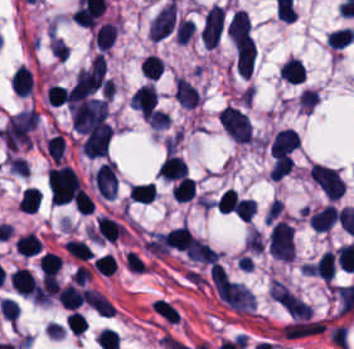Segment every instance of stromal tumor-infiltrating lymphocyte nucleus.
Wrapping results in <instances>:
<instances>
[{
    "label": "stromal tumor-infiltrating lymphocyte nucleus",
    "instance_id": "bc302bb0",
    "mask_svg": "<svg viewBox=\"0 0 354 349\" xmlns=\"http://www.w3.org/2000/svg\"><path fill=\"white\" fill-rule=\"evenodd\" d=\"M224 21L225 11L221 6L214 4L210 9L201 30L202 42L206 48L217 46L221 37Z\"/></svg>",
    "mask_w": 354,
    "mask_h": 349
},
{
    "label": "stromal tumor-infiltrating lymphocyte nucleus",
    "instance_id": "52c7bb5b",
    "mask_svg": "<svg viewBox=\"0 0 354 349\" xmlns=\"http://www.w3.org/2000/svg\"><path fill=\"white\" fill-rule=\"evenodd\" d=\"M158 94L154 86L143 84L132 94L129 104L145 116H153Z\"/></svg>",
    "mask_w": 354,
    "mask_h": 349
},
{
    "label": "stromal tumor-infiltrating lymphocyte nucleus",
    "instance_id": "3290ff9b",
    "mask_svg": "<svg viewBox=\"0 0 354 349\" xmlns=\"http://www.w3.org/2000/svg\"><path fill=\"white\" fill-rule=\"evenodd\" d=\"M174 16L175 4L172 0L163 6L153 18L150 31L153 39L159 41L170 34L174 26Z\"/></svg>",
    "mask_w": 354,
    "mask_h": 349
},
{
    "label": "stromal tumor-infiltrating lymphocyte nucleus",
    "instance_id": "abfb95fc",
    "mask_svg": "<svg viewBox=\"0 0 354 349\" xmlns=\"http://www.w3.org/2000/svg\"><path fill=\"white\" fill-rule=\"evenodd\" d=\"M298 148V138L293 128H286L274 134L269 144L270 157L287 154Z\"/></svg>",
    "mask_w": 354,
    "mask_h": 349
},
{
    "label": "stromal tumor-infiltrating lymphocyte nucleus",
    "instance_id": "9ea309e8",
    "mask_svg": "<svg viewBox=\"0 0 354 349\" xmlns=\"http://www.w3.org/2000/svg\"><path fill=\"white\" fill-rule=\"evenodd\" d=\"M174 100L182 108H196L198 103L197 91L183 77L174 80Z\"/></svg>",
    "mask_w": 354,
    "mask_h": 349
},
{
    "label": "stromal tumor-infiltrating lymphocyte nucleus",
    "instance_id": "f3e2335f",
    "mask_svg": "<svg viewBox=\"0 0 354 349\" xmlns=\"http://www.w3.org/2000/svg\"><path fill=\"white\" fill-rule=\"evenodd\" d=\"M10 287L18 293L31 295L37 282L33 274L24 267H17L10 273Z\"/></svg>",
    "mask_w": 354,
    "mask_h": 349
},
{
    "label": "stromal tumor-infiltrating lymphocyte nucleus",
    "instance_id": "4f13568d",
    "mask_svg": "<svg viewBox=\"0 0 354 349\" xmlns=\"http://www.w3.org/2000/svg\"><path fill=\"white\" fill-rule=\"evenodd\" d=\"M279 77L291 84H300L305 79V68L302 61L288 57L279 67Z\"/></svg>",
    "mask_w": 354,
    "mask_h": 349
},
{
    "label": "stromal tumor-infiltrating lymphocyte nucleus",
    "instance_id": "2a367800",
    "mask_svg": "<svg viewBox=\"0 0 354 349\" xmlns=\"http://www.w3.org/2000/svg\"><path fill=\"white\" fill-rule=\"evenodd\" d=\"M312 230L328 231L337 222V212L332 206H325L309 217Z\"/></svg>",
    "mask_w": 354,
    "mask_h": 349
},
{
    "label": "stromal tumor-infiltrating lymphocyte nucleus",
    "instance_id": "4803ca6d",
    "mask_svg": "<svg viewBox=\"0 0 354 349\" xmlns=\"http://www.w3.org/2000/svg\"><path fill=\"white\" fill-rule=\"evenodd\" d=\"M158 174L166 179L175 181L187 176V166L182 157L169 154L164 160Z\"/></svg>",
    "mask_w": 354,
    "mask_h": 349
},
{
    "label": "stromal tumor-infiltrating lymphocyte nucleus",
    "instance_id": "4245b91a",
    "mask_svg": "<svg viewBox=\"0 0 354 349\" xmlns=\"http://www.w3.org/2000/svg\"><path fill=\"white\" fill-rule=\"evenodd\" d=\"M56 298L61 307L76 310L83 303V292L68 283L57 292Z\"/></svg>",
    "mask_w": 354,
    "mask_h": 349
},
{
    "label": "stromal tumor-infiltrating lymphocyte nucleus",
    "instance_id": "4c9ddf68",
    "mask_svg": "<svg viewBox=\"0 0 354 349\" xmlns=\"http://www.w3.org/2000/svg\"><path fill=\"white\" fill-rule=\"evenodd\" d=\"M116 35V28L111 22H103L94 32V41L99 51H107Z\"/></svg>",
    "mask_w": 354,
    "mask_h": 349
},
{
    "label": "stromal tumor-infiltrating lymphocyte nucleus",
    "instance_id": "2761f720",
    "mask_svg": "<svg viewBox=\"0 0 354 349\" xmlns=\"http://www.w3.org/2000/svg\"><path fill=\"white\" fill-rule=\"evenodd\" d=\"M14 247L22 255L33 256L40 253L42 242L34 233H27L15 239Z\"/></svg>",
    "mask_w": 354,
    "mask_h": 349
},
{
    "label": "stromal tumor-infiltrating lymphocyte nucleus",
    "instance_id": "3c572f05",
    "mask_svg": "<svg viewBox=\"0 0 354 349\" xmlns=\"http://www.w3.org/2000/svg\"><path fill=\"white\" fill-rule=\"evenodd\" d=\"M42 196L38 189L33 187H25L18 201L19 211L34 213L37 209Z\"/></svg>",
    "mask_w": 354,
    "mask_h": 349
},
{
    "label": "stromal tumor-infiltrating lymphocyte nucleus",
    "instance_id": "42bb06b2",
    "mask_svg": "<svg viewBox=\"0 0 354 349\" xmlns=\"http://www.w3.org/2000/svg\"><path fill=\"white\" fill-rule=\"evenodd\" d=\"M196 181L192 177H184L172 186V195L177 201H191L195 193Z\"/></svg>",
    "mask_w": 354,
    "mask_h": 349
},
{
    "label": "stromal tumor-infiltrating lymphocyte nucleus",
    "instance_id": "9e4306bb",
    "mask_svg": "<svg viewBox=\"0 0 354 349\" xmlns=\"http://www.w3.org/2000/svg\"><path fill=\"white\" fill-rule=\"evenodd\" d=\"M354 39L352 28H339L328 32L326 42L331 48H343L348 46Z\"/></svg>",
    "mask_w": 354,
    "mask_h": 349
},
{
    "label": "stromal tumor-infiltrating lymphocyte nucleus",
    "instance_id": "04cf8593",
    "mask_svg": "<svg viewBox=\"0 0 354 349\" xmlns=\"http://www.w3.org/2000/svg\"><path fill=\"white\" fill-rule=\"evenodd\" d=\"M129 198L133 201L151 202L155 196L154 182L132 185L128 190Z\"/></svg>",
    "mask_w": 354,
    "mask_h": 349
},
{
    "label": "stromal tumor-infiltrating lymphocyte nucleus",
    "instance_id": "e9af9c67",
    "mask_svg": "<svg viewBox=\"0 0 354 349\" xmlns=\"http://www.w3.org/2000/svg\"><path fill=\"white\" fill-rule=\"evenodd\" d=\"M38 266L42 277L53 274L61 267V259L59 255L49 251H45L38 257Z\"/></svg>",
    "mask_w": 354,
    "mask_h": 349
},
{
    "label": "stromal tumor-infiltrating lymphocyte nucleus",
    "instance_id": "782c7336",
    "mask_svg": "<svg viewBox=\"0 0 354 349\" xmlns=\"http://www.w3.org/2000/svg\"><path fill=\"white\" fill-rule=\"evenodd\" d=\"M293 166V158L287 154H279L272 164L269 174L273 179L280 180Z\"/></svg>",
    "mask_w": 354,
    "mask_h": 349
},
{
    "label": "stromal tumor-infiltrating lymphocyte nucleus",
    "instance_id": "cac63f63",
    "mask_svg": "<svg viewBox=\"0 0 354 349\" xmlns=\"http://www.w3.org/2000/svg\"><path fill=\"white\" fill-rule=\"evenodd\" d=\"M150 305L152 310L163 320L177 323L179 314L168 301L157 298L156 300L151 302Z\"/></svg>",
    "mask_w": 354,
    "mask_h": 349
},
{
    "label": "stromal tumor-infiltrating lymphocyte nucleus",
    "instance_id": "2e467ee5",
    "mask_svg": "<svg viewBox=\"0 0 354 349\" xmlns=\"http://www.w3.org/2000/svg\"><path fill=\"white\" fill-rule=\"evenodd\" d=\"M163 64L158 56L148 55L140 64L139 71L145 77L157 79L162 71Z\"/></svg>",
    "mask_w": 354,
    "mask_h": 349
},
{
    "label": "stromal tumor-infiltrating lymphocyte nucleus",
    "instance_id": "7eef579d",
    "mask_svg": "<svg viewBox=\"0 0 354 349\" xmlns=\"http://www.w3.org/2000/svg\"><path fill=\"white\" fill-rule=\"evenodd\" d=\"M72 203L76 211L82 215H90L95 206L91 196L81 187L73 197Z\"/></svg>",
    "mask_w": 354,
    "mask_h": 349
},
{
    "label": "stromal tumor-infiltrating lymphocyte nucleus",
    "instance_id": "c26a33f6",
    "mask_svg": "<svg viewBox=\"0 0 354 349\" xmlns=\"http://www.w3.org/2000/svg\"><path fill=\"white\" fill-rule=\"evenodd\" d=\"M45 148L48 157L55 162H60L63 154L64 142L61 136L57 133L46 139Z\"/></svg>",
    "mask_w": 354,
    "mask_h": 349
},
{
    "label": "stromal tumor-infiltrating lymphocyte nucleus",
    "instance_id": "3e0999b9",
    "mask_svg": "<svg viewBox=\"0 0 354 349\" xmlns=\"http://www.w3.org/2000/svg\"><path fill=\"white\" fill-rule=\"evenodd\" d=\"M239 202L240 199L236 190L226 189L217 204V211L226 214L232 212Z\"/></svg>",
    "mask_w": 354,
    "mask_h": 349
},
{
    "label": "stromal tumor-infiltrating lymphocyte nucleus",
    "instance_id": "a0a3295f",
    "mask_svg": "<svg viewBox=\"0 0 354 349\" xmlns=\"http://www.w3.org/2000/svg\"><path fill=\"white\" fill-rule=\"evenodd\" d=\"M256 211L254 200L241 199L235 214L240 220H251Z\"/></svg>",
    "mask_w": 354,
    "mask_h": 349
}]
</instances>
